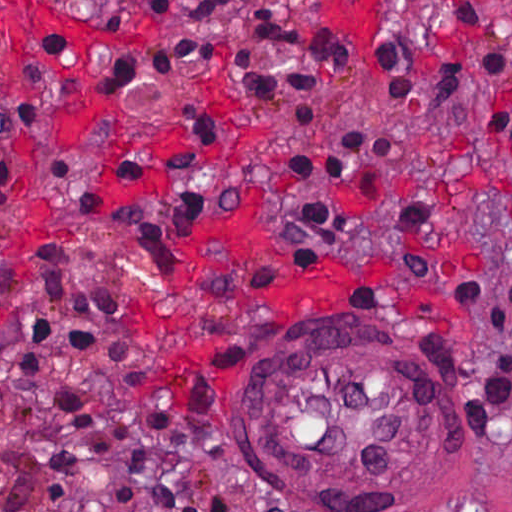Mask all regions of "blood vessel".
<instances>
[{
	"instance_id": "1",
	"label": "blood vessel",
	"mask_w": 512,
	"mask_h": 512,
	"mask_svg": "<svg viewBox=\"0 0 512 512\" xmlns=\"http://www.w3.org/2000/svg\"><path fill=\"white\" fill-rule=\"evenodd\" d=\"M248 439L281 482L338 504H393L432 489L448 459L440 378L384 331L292 337L255 361Z\"/></svg>"
}]
</instances>
